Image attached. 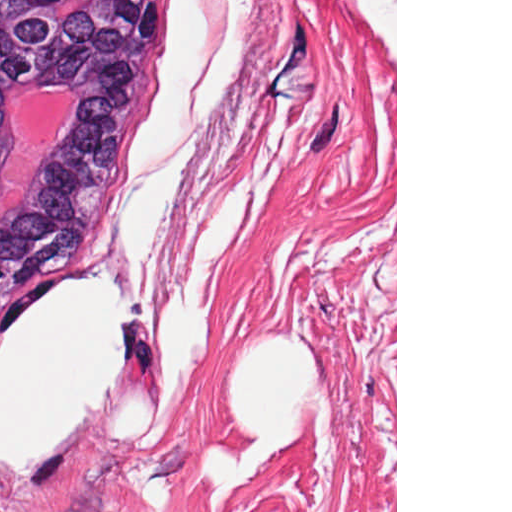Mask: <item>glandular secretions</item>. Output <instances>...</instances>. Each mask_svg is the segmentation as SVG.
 <instances>
[{
  "label": "glandular secretions",
  "instance_id": "obj_1",
  "mask_svg": "<svg viewBox=\"0 0 512 512\" xmlns=\"http://www.w3.org/2000/svg\"><path fill=\"white\" fill-rule=\"evenodd\" d=\"M71 90H72V89H71ZM35 92H37V91H35ZM35 92L28 93V94H26V95H25V97L23 98V100H22V102H21V105H20V108H19V110H18V113H17L16 117H15V118L13 119V121H12L11 128H10V132H9V136H8V139H7V142H6L5 149H6V147H7L8 142L12 139V130H13V128H14V126H15V124H16V122H17V120H18V118H19V116H20V114H21V112H22V110H23V108H24V106H25V104H26V102H27L28 98H29L32 94H34ZM72 92H73V90H72ZM73 93H74V92H73ZM74 94H75V93H74ZM5 149H4V151H5ZM0 165H1V164H0ZM32 170H33V169H32ZM32 170H31V172H30L29 177H28V178H27V180L25 181V183H24V185H23L22 189L20 190V192H19L18 196L16 197V199L12 202V204H11V205H10V206L5 210V212L3 213V215L0 217V221H1L2 219H4V218L8 215V213H9V211H10V209H11L12 205H13L15 202H17V201L21 198V196L25 193V191L27 190L28 185H29V182H30V178H31Z\"/></svg>",
  "mask_w": 512,
  "mask_h": 512
}]
</instances>
